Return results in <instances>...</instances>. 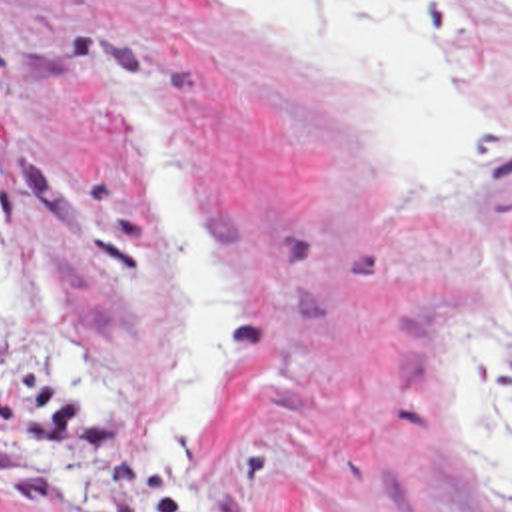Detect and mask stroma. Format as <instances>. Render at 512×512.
<instances>
[{"label":"stroma","instance_id":"1","mask_svg":"<svg viewBox=\"0 0 512 512\" xmlns=\"http://www.w3.org/2000/svg\"><path fill=\"white\" fill-rule=\"evenodd\" d=\"M410 1L478 137L448 197L220 0H0V512H512L452 386L512 258V0ZM106 65L162 111L222 284V402L172 494L176 228Z\"/></svg>","mask_w":512,"mask_h":512}]
</instances>
